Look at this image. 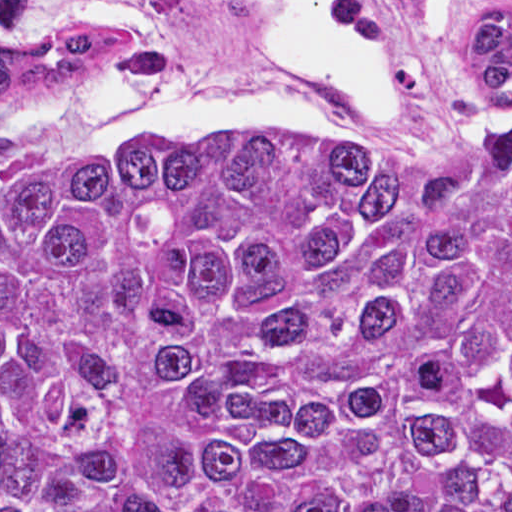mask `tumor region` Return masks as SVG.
Listing matches in <instances>:
<instances>
[{
  "instance_id": "obj_1",
  "label": "tumor region",
  "mask_w": 512,
  "mask_h": 512,
  "mask_svg": "<svg viewBox=\"0 0 512 512\" xmlns=\"http://www.w3.org/2000/svg\"><path fill=\"white\" fill-rule=\"evenodd\" d=\"M435 5L424 173L228 128L0 181V512H512V288L462 253L512 279V0ZM29 9L0 97L169 56Z\"/></svg>"
}]
</instances>
